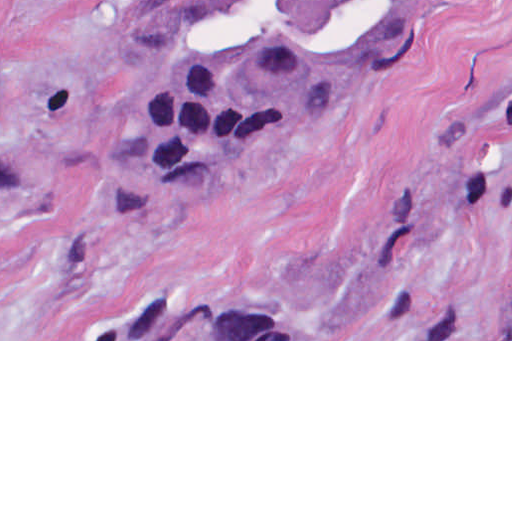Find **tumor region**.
<instances>
[{
  "label": "tumor region",
  "instance_id": "1",
  "mask_svg": "<svg viewBox=\"0 0 512 512\" xmlns=\"http://www.w3.org/2000/svg\"><path fill=\"white\" fill-rule=\"evenodd\" d=\"M440 2L130 0V89L167 178L220 174L313 124L382 79ZM0 162L55 159L44 141L0 128ZM113 339H298V312L290 299L157 302Z\"/></svg>",
  "mask_w": 512,
  "mask_h": 512
}]
</instances>
